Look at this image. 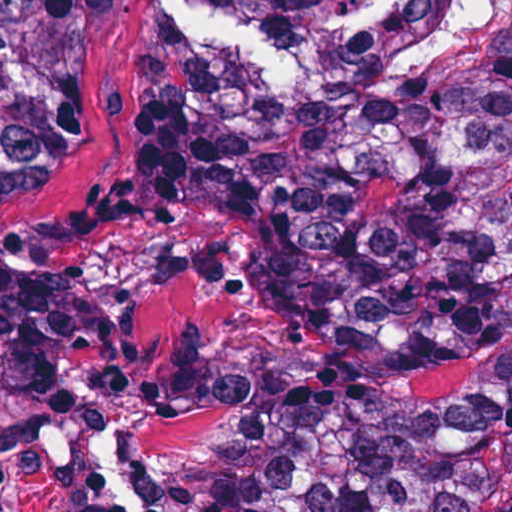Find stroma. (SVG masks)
<instances>
[{
  "instance_id": "1",
  "label": "stroma",
  "mask_w": 512,
  "mask_h": 512,
  "mask_svg": "<svg viewBox=\"0 0 512 512\" xmlns=\"http://www.w3.org/2000/svg\"><path fill=\"white\" fill-rule=\"evenodd\" d=\"M331 0H124L89 69L85 135L50 186L0 204V253L107 309V377L0 404V512H239L291 404L307 325L249 212L194 183L156 209L82 210L129 189L165 58L206 75H312ZM188 362L193 402L173 394Z\"/></svg>"
}]
</instances>
